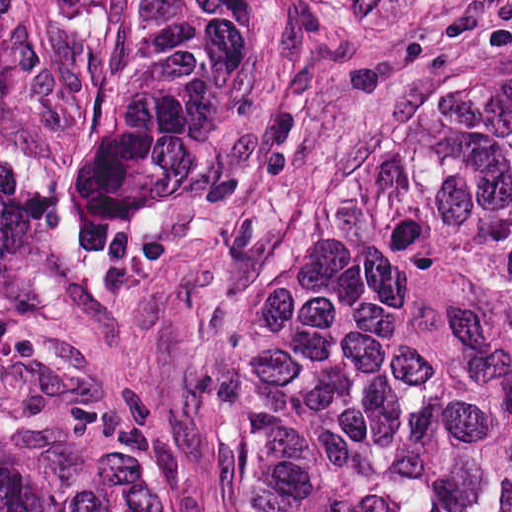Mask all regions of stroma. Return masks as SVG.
Listing matches in <instances>:
<instances>
[{"label": "stroma", "mask_w": 512, "mask_h": 512, "mask_svg": "<svg viewBox=\"0 0 512 512\" xmlns=\"http://www.w3.org/2000/svg\"><path fill=\"white\" fill-rule=\"evenodd\" d=\"M0 401L77 403L221 512L220 315L0 244Z\"/></svg>", "instance_id": "obj_1"}]
</instances>
